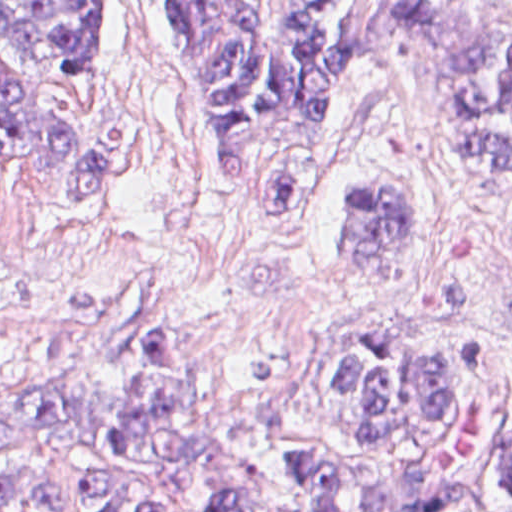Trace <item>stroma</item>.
Returning <instances> with one entry per match:
<instances>
[{"instance_id": "obj_1", "label": "stroma", "mask_w": 512, "mask_h": 512, "mask_svg": "<svg viewBox=\"0 0 512 512\" xmlns=\"http://www.w3.org/2000/svg\"><path fill=\"white\" fill-rule=\"evenodd\" d=\"M314 1L337 27L361 2ZM0 62L43 84L98 160V208L81 213L49 208L25 174L0 168V474L38 472L65 488L84 480L100 453L11 431L5 415L70 390L123 389L137 338L166 328L181 330L198 401L221 419L260 416L316 374L314 343L387 314L501 343L512 402V182L438 164L440 121L378 65L340 98L315 219L266 228L216 161L141 0H116L83 74L93 79L2 43ZM381 174L410 198L414 232L406 257L370 265L351 256L340 208Z\"/></svg>"}]
</instances>
